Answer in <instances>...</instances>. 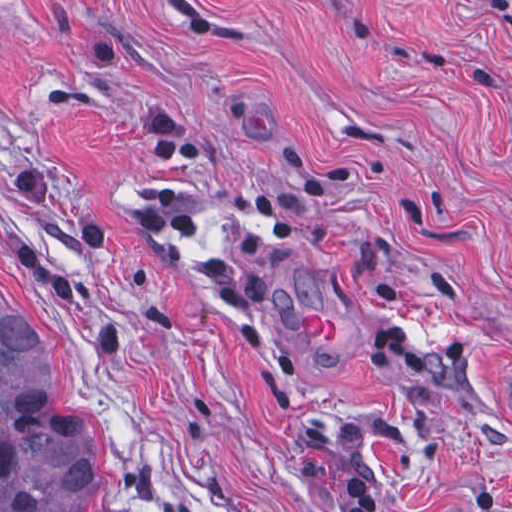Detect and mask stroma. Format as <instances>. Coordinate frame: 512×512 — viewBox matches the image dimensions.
Wrapping results in <instances>:
<instances>
[{"label":"stroma","instance_id":"stroma-1","mask_svg":"<svg viewBox=\"0 0 512 512\" xmlns=\"http://www.w3.org/2000/svg\"><path fill=\"white\" fill-rule=\"evenodd\" d=\"M0 305L99 512H512V0H0Z\"/></svg>","mask_w":512,"mask_h":512}]
</instances>
